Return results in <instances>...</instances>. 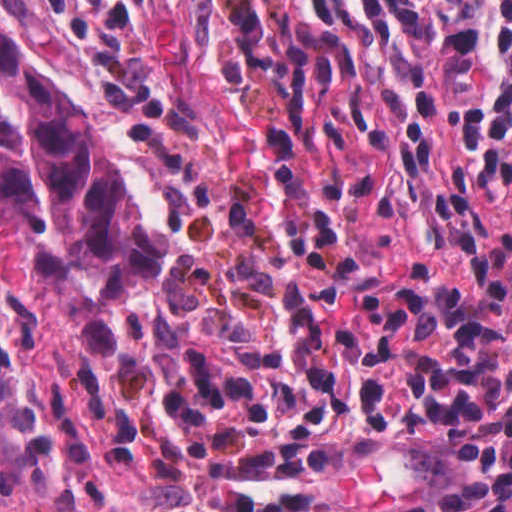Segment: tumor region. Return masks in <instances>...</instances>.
I'll list each match as a JSON object with an SVG mask.
<instances>
[{
    "mask_svg": "<svg viewBox=\"0 0 512 512\" xmlns=\"http://www.w3.org/2000/svg\"><path fill=\"white\" fill-rule=\"evenodd\" d=\"M88 67L44 0H0V224L43 233V273L78 305L93 352L111 348L105 311L128 285L159 273L164 234L126 197L90 118L31 66Z\"/></svg>",
    "mask_w": 512,
    "mask_h": 512,
    "instance_id": "1",
    "label": "tumor region"
}]
</instances>
